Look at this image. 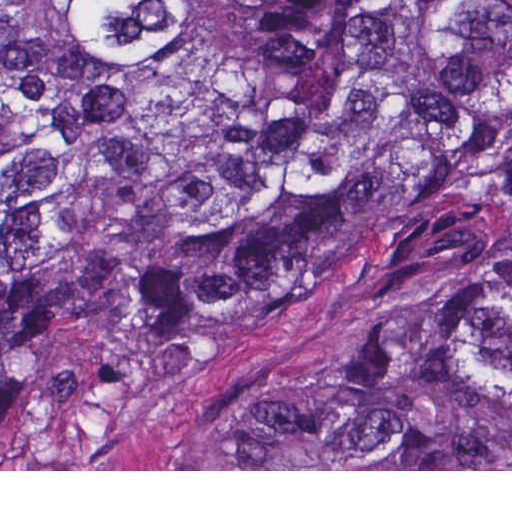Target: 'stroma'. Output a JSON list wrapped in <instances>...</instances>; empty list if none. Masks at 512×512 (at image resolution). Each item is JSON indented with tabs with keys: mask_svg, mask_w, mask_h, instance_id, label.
I'll list each match as a JSON object with an SVG mask.
<instances>
[{
	"mask_svg": "<svg viewBox=\"0 0 512 512\" xmlns=\"http://www.w3.org/2000/svg\"><path fill=\"white\" fill-rule=\"evenodd\" d=\"M512 255V206L378 250L290 289L206 365L56 403L0 429V471H512L227 469L239 416L298 372L398 324L462 276Z\"/></svg>",
	"mask_w": 512,
	"mask_h": 512,
	"instance_id": "1",
	"label": "stroma"
}]
</instances>
